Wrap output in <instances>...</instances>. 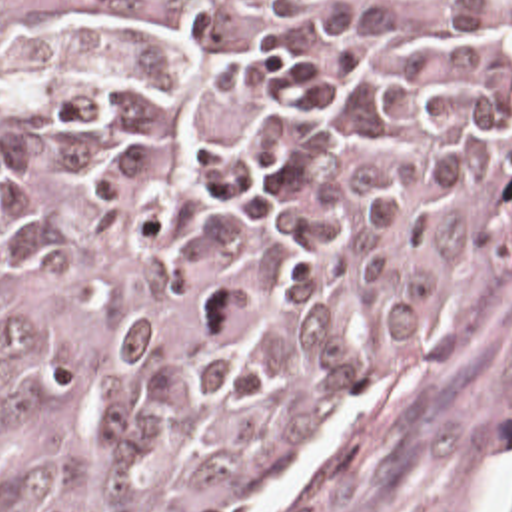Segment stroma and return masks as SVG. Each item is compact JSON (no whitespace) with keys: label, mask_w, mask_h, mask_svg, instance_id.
Returning a JSON list of instances; mask_svg holds the SVG:
<instances>
[{"label":"stroma","mask_w":512,"mask_h":512,"mask_svg":"<svg viewBox=\"0 0 512 512\" xmlns=\"http://www.w3.org/2000/svg\"><path fill=\"white\" fill-rule=\"evenodd\" d=\"M512 455V190L437 282L357 421L285 487L233 512H465ZM499 512H512V475Z\"/></svg>","instance_id":"obj_1"}]
</instances>
